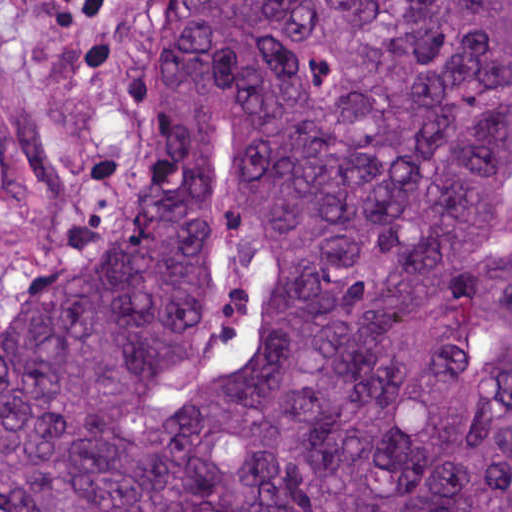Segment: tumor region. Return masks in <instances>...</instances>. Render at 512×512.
I'll list each match as a JSON object with an SVG mask.
<instances>
[{
    "label": "tumor region",
    "mask_w": 512,
    "mask_h": 512,
    "mask_svg": "<svg viewBox=\"0 0 512 512\" xmlns=\"http://www.w3.org/2000/svg\"><path fill=\"white\" fill-rule=\"evenodd\" d=\"M0 512H512V0H160Z\"/></svg>",
    "instance_id": "obj_1"
}]
</instances>
